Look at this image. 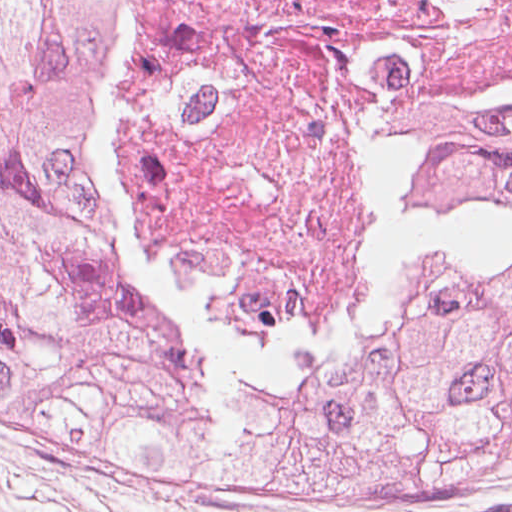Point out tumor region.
<instances>
[{"instance_id": "obj_1", "label": "tumor region", "mask_w": 512, "mask_h": 512, "mask_svg": "<svg viewBox=\"0 0 512 512\" xmlns=\"http://www.w3.org/2000/svg\"><path fill=\"white\" fill-rule=\"evenodd\" d=\"M125 0H0V270L203 313L100 159ZM421 224L383 312L340 343L512 379V114L414 138Z\"/></svg>"}]
</instances>
